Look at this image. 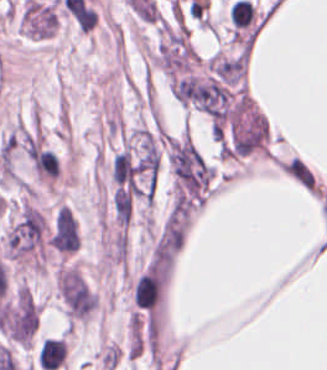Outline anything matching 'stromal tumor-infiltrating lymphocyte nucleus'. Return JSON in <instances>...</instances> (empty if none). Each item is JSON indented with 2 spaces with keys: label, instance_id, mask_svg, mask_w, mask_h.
Here are the masks:
<instances>
[{
  "label": "stromal tumor-infiltrating lymphocyte nucleus",
  "instance_id": "stromal-tumor-infiltrating-lymphocyte-nucleus-1",
  "mask_svg": "<svg viewBox=\"0 0 327 370\" xmlns=\"http://www.w3.org/2000/svg\"><path fill=\"white\" fill-rule=\"evenodd\" d=\"M67 352L65 340L58 337H44L37 354L43 370H56L63 365Z\"/></svg>",
  "mask_w": 327,
  "mask_h": 370
}]
</instances>
